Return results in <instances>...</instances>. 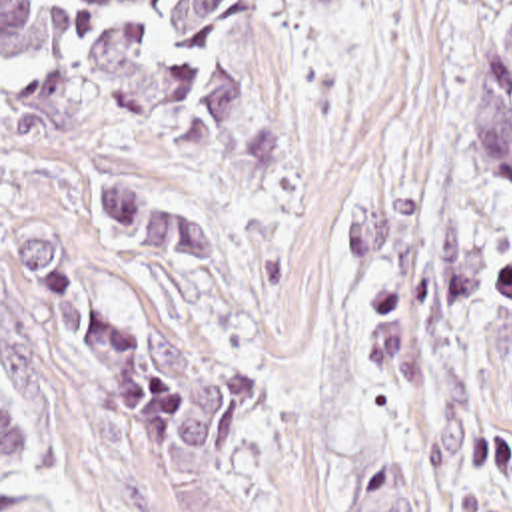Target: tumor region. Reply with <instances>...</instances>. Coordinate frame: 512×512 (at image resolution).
<instances>
[{
    "mask_svg": "<svg viewBox=\"0 0 512 512\" xmlns=\"http://www.w3.org/2000/svg\"><path fill=\"white\" fill-rule=\"evenodd\" d=\"M345 0H297L299 8L331 6ZM512 8V0H501ZM469 160L495 180H512V32L487 58L479 90L467 114ZM395 204L355 208L343 216L337 244L355 254L383 252L393 236ZM443 212V284L453 302L471 306L479 298L487 276V234L439 206ZM351 512H423L417 497L385 460H375L361 489L351 495Z\"/></svg>",
    "mask_w": 512,
    "mask_h": 512,
    "instance_id": "e687c5a6",
    "label": "tumor region"
}]
</instances>
